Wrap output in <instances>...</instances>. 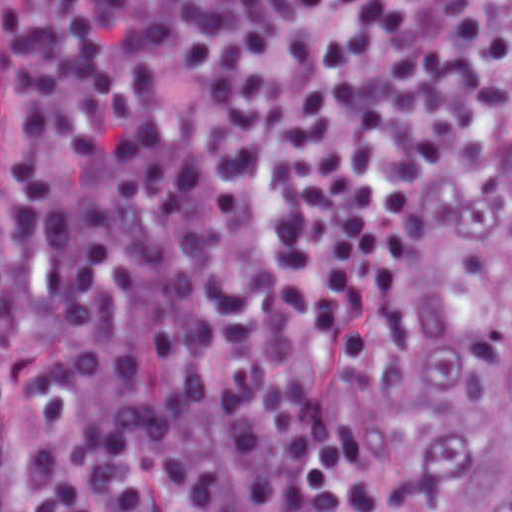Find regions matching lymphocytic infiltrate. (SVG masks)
Segmentation results:
<instances>
[{
    "instance_id": "f902f5d3",
    "label": "lymphocytic infiltrate",
    "mask_w": 512,
    "mask_h": 512,
    "mask_svg": "<svg viewBox=\"0 0 512 512\" xmlns=\"http://www.w3.org/2000/svg\"><path fill=\"white\" fill-rule=\"evenodd\" d=\"M511 135L512 0H4L20 512H449L408 393ZM312 343L411 424L400 476H366Z\"/></svg>"
}]
</instances>
